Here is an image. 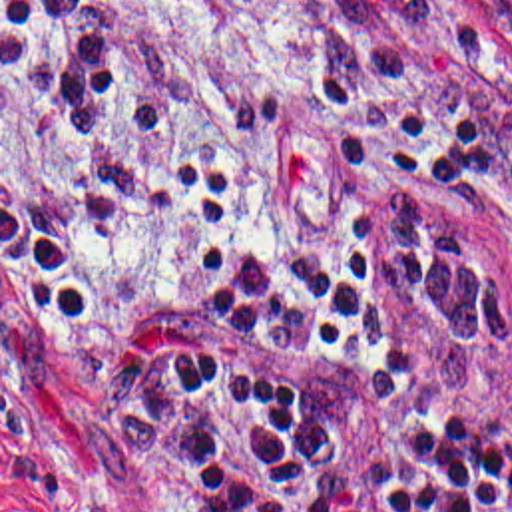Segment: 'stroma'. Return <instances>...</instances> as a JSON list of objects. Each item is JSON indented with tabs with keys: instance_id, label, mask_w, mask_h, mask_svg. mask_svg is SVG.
<instances>
[{
	"instance_id": "35a3bbf8",
	"label": "stroma",
	"mask_w": 512,
	"mask_h": 512,
	"mask_svg": "<svg viewBox=\"0 0 512 512\" xmlns=\"http://www.w3.org/2000/svg\"><path fill=\"white\" fill-rule=\"evenodd\" d=\"M86 42L131 85L189 97L145 137H80L4 36L0 0V512H173L159 460L106 414L54 313L2 263V197L60 233L121 324L187 318L195 277L167 207L175 161L233 173L227 243L341 253L307 76L480 141L476 181L442 215L512 289V34L490 0H82Z\"/></svg>"
}]
</instances>
